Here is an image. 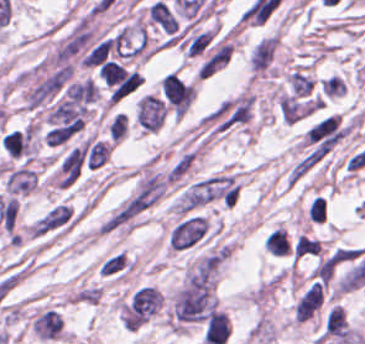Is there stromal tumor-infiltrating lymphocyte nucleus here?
Masks as SVG:
<instances>
[{
	"instance_id": "abfb95fc",
	"label": "stromal tumor-infiltrating lymphocyte nucleus",
	"mask_w": 365,
	"mask_h": 344,
	"mask_svg": "<svg viewBox=\"0 0 365 344\" xmlns=\"http://www.w3.org/2000/svg\"><path fill=\"white\" fill-rule=\"evenodd\" d=\"M264 245L268 252L277 255L290 253V243L284 227H277L264 238Z\"/></svg>"
},
{
	"instance_id": "f3e2335f",
	"label": "stromal tumor-infiltrating lymphocyte nucleus",
	"mask_w": 365,
	"mask_h": 344,
	"mask_svg": "<svg viewBox=\"0 0 365 344\" xmlns=\"http://www.w3.org/2000/svg\"><path fill=\"white\" fill-rule=\"evenodd\" d=\"M128 129V115L124 112H117L110 120L107 133L110 141H117L125 136Z\"/></svg>"
},
{
	"instance_id": "9ea309e8",
	"label": "stromal tumor-infiltrating lymphocyte nucleus",
	"mask_w": 365,
	"mask_h": 344,
	"mask_svg": "<svg viewBox=\"0 0 365 344\" xmlns=\"http://www.w3.org/2000/svg\"><path fill=\"white\" fill-rule=\"evenodd\" d=\"M320 249L321 243L319 239L301 233L295 242L294 257L297 259L314 255L320 252Z\"/></svg>"
},
{
	"instance_id": "3290ff9b",
	"label": "stromal tumor-infiltrating lymphocyte nucleus",
	"mask_w": 365,
	"mask_h": 344,
	"mask_svg": "<svg viewBox=\"0 0 365 344\" xmlns=\"http://www.w3.org/2000/svg\"><path fill=\"white\" fill-rule=\"evenodd\" d=\"M146 17L149 22L163 30L172 32L177 28L176 17L165 1L155 0L146 8Z\"/></svg>"
},
{
	"instance_id": "52c7bb5b",
	"label": "stromal tumor-infiltrating lymphocyte nucleus",
	"mask_w": 365,
	"mask_h": 344,
	"mask_svg": "<svg viewBox=\"0 0 365 344\" xmlns=\"http://www.w3.org/2000/svg\"><path fill=\"white\" fill-rule=\"evenodd\" d=\"M231 324L226 313L211 309L207 315L203 340L207 344H224L230 332Z\"/></svg>"
},
{
	"instance_id": "bc302bb0",
	"label": "stromal tumor-infiltrating lymphocyte nucleus",
	"mask_w": 365,
	"mask_h": 344,
	"mask_svg": "<svg viewBox=\"0 0 365 344\" xmlns=\"http://www.w3.org/2000/svg\"><path fill=\"white\" fill-rule=\"evenodd\" d=\"M160 90L172 110L185 111L195 97L192 83L170 71L162 77Z\"/></svg>"
}]
</instances>
